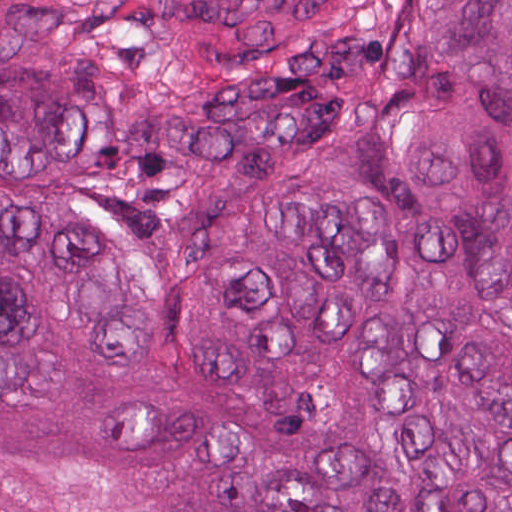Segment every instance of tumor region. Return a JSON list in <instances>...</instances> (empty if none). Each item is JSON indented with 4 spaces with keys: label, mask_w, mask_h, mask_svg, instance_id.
Wrapping results in <instances>:
<instances>
[{
    "label": "tumor region",
    "mask_w": 512,
    "mask_h": 512,
    "mask_svg": "<svg viewBox=\"0 0 512 512\" xmlns=\"http://www.w3.org/2000/svg\"><path fill=\"white\" fill-rule=\"evenodd\" d=\"M1 512H512V1H1Z\"/></svg>",
    "instance_id": "tumor-region-1"
}]
</instances>
